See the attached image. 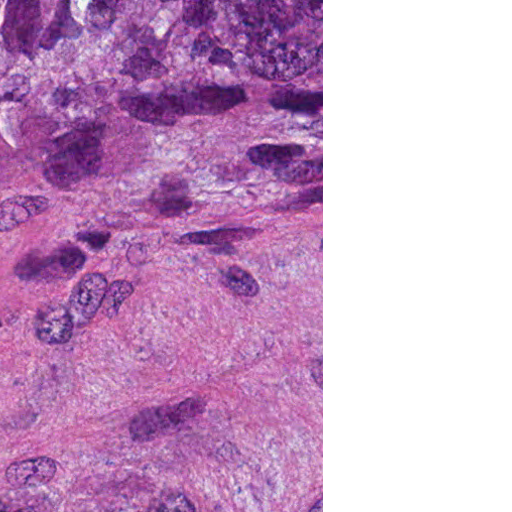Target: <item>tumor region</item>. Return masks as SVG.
Masks as SVG:
<instances>
[{
    "label": "tumor region",
    "instance_id": "tumor-region-1",
    "mask_svg": "<svg viewBox=\"0 0 512 512\" xmlns=\"http://www.w3.org/2000/svg\"><path fill=\"white\" fill-rule=\"evenodd\" d=\"M35 205L36 1H0V219ZM69 512H161V465L108 481Z\"/></svg>",
    "mask_w": 512,
    "mask_h": 512
}]
</instances>
